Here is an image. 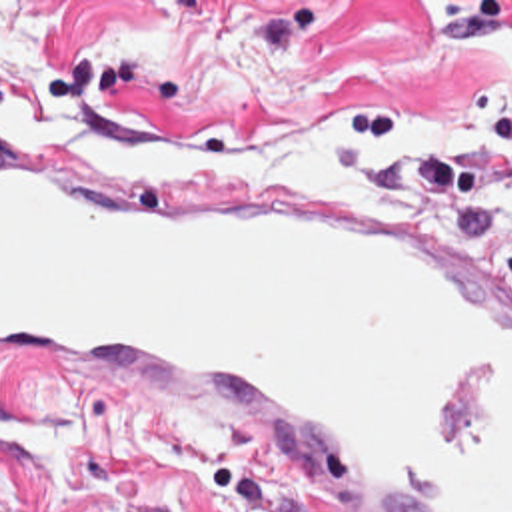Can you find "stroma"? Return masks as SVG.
<instances>
[{"mask_svg": "<svg viewBox=\"0 0 512 512\" xmlns=\"http://www.w3.org/2000/svg\"><path fill=\"white\" fill-rule=\"evenodd\" d=\"M0 122L204 152L512 284V0H0ZM0 423L76 425L104 461L0 449V512H304L178 405L2 391Z\"/></svg>", "mask_w": 512, "mask_h": 512, "instance_id": "stroma-1", "label": "stroma"}]
</instances>
